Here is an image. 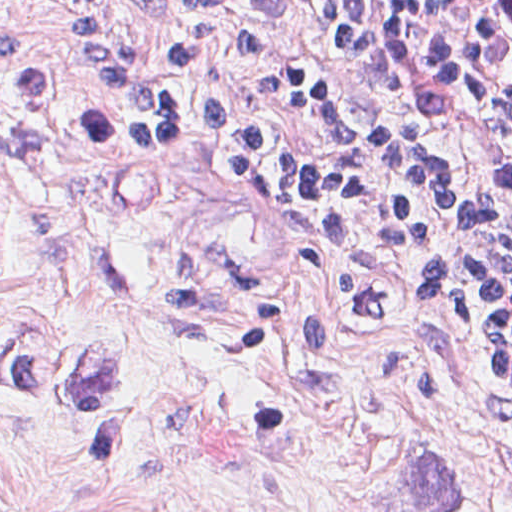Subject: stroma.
Returning <instances> with one entry per match:
<instances>
[{"label": "stroma", "instance_id": "stroma-1", "mask_svg": "<svg viewBox=\"0 0 512 512\" xmlns=\"http://www.w3.org/2000/svg\"><path fill=\"white\" fill-rule=\"evenodd\" d=\"M229 1L312 64L273 0ZM99 3L171 94L368 146L355 103L324 136L220 43L169 76L172 31ZM428 261L323 254L274 193L134 142L62 0H0V512H512V392L407 291Z\"/></svg>", "mask_w": 512, "mask_h": 512}]
</instances>
